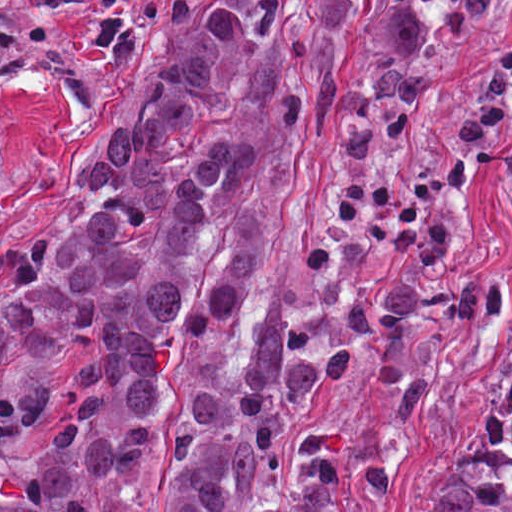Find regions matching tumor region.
<instances>
[{"label": "tumor region", "mask_w": 512, "mask_h": 512, "mask_svg": "<svg viewBox=\"0 0 512 512\" xmlns=\"http://www.w3.org/2000/svg\"><path fill=\"white\" fill-rule=\"evenodd\" d=\"M306 124L21 253L0 302V512H143L135 473L187 342L206 377L186 402L166 512H341L388 484L385 454H337L336 388L423 399L417 322L500 314L509 286L381 280L343 310H293L276 215ZM406 512H512V366L483 428Z\"/></svg>", "instance_id": "e687c5a6"}]
</instances>
